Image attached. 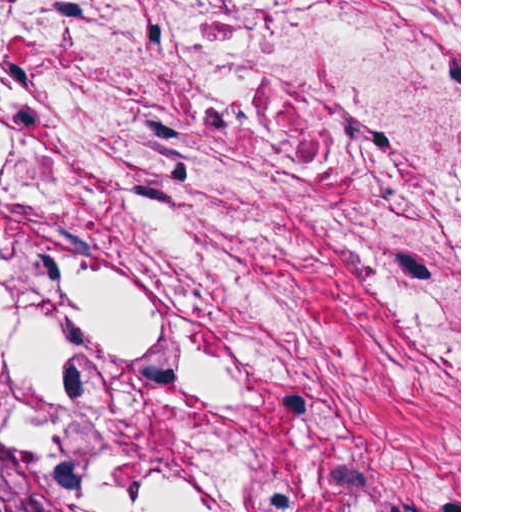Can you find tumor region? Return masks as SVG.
<instances>
[{"instance_id": "e687c5a6", "label": "tumor region", "mask_w": 512, "mask_h": 512, "mask_svg": "<svg viewBox=\"0 0 512 512\" xmlns=\"http://www.w3.org/2000/svg\"><path fill=\"white\" fill-rule=\"evenodd\" d=\"M0 512H65L26 440L1 408Z\"/></svg>"}]
</instances>
